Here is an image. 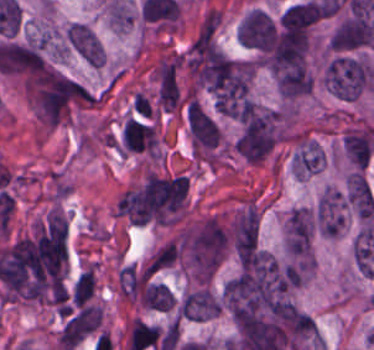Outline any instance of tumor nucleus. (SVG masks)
I'll use <instances>...</instances> for the list:
<instances>
[{
  "mask_svg": "<svg viewBox=\"0 0 374 350\" xmlns=\"http://www.w3.org/2000/svg\"><path fill=\"white\" fill-rule=\"evenodd\" d=\"M231 239L240 265L260 245V215L253 203H246L236 216Z\"/></svg>",
  "mask_w": 374,
  "mask_h": 350,
  "instance_id": "5ab6c2c4",
  "label": "tumor nucleus"
},
{
  "mask_svg": "<svg viewBox=\"0 0 374 350\" xmlns=\"http://www.w3.org/2000/svg\"><path fill=\"white\" fill-rule=\"evenodd\" d=\"M186 122L194 149L211 150L220 143V128L215 118L195 99H188Z\"/></svg>",
  "mask_w": 374,
  "mask_h": 350,
  "instance_id": "2cbd58db",
  "label": "tumor nucleus"
},
{
  "mask_svg": "<svg viewBox=\"0 0 374 350\" xmlns=\"http://www.w3.org/2000/svg\"><path fill=\"white\" fill-rule=\"evenodd\" d=\"M102 320V305L83 304L66 316L58 346L61 350H73L97 329Z\"/></svg>",
  "mask_w": 374,
  "mask_h": 350,
  "instance_id": "8643909e",
  "label": "tumor nucleus"
},
{
  "mask_svg": "<svg viewBox=\"0 0 374 350\" xmlns=\"http://www.w3.org/2000/svg\"><path fill=\"white\" fill-rule=\"evenodd\" d=\"M96 275L94 265L80 273L74 283L71 298L75 306H81L95 293Z\"/></svg>",
  "mask_w": 374,
  "mask_h": 350,
  "instance_id": "8087334f",
  "label": "tumor nucleus"
},
{
  "mask_svg": "<svg viewBox=\"0 0 374 350\" xmlns=\"http://www.w3.org/2000/svg\"><path fill=\"white\" fill-rule=\"evenodd\" d=\"M323 79L330 93L342 99H358L374 89L373 67L350 53L332 56Z\"/></svg>",
  "mask_w": 374,
  "mask_h": 350,
  "instance_id": "2f306a5c",
  "label": "tumor nucleus"
},
{
  "mask_svg": "<svg viewBox=\"0 0 374 350\" xmlns=\"http://www.w3.org/2000/svg\"><path fill=\"white\" fill-rule=\"evenodd\" d=\"M66 40L75 52L82 56L93 66L103 63L102 42L85 22H71L66 31Z\"/></svg>",
  "mask_w": 374,
  "mask_h": 350,
  "instance_id": "2083b535",
  "label": "tumor nucleus"
},
{
  "mask_svg": "<svg viewBox=\"0 0 374 350\" xmlns=\"http://www.w3.org/2000/svg\"><path fill=\"white\" fill-rule=\"evenodd\" d=\"M374 35V25L361 15H348L329 39L334 51L350 52L367 46Z\"/></svg>",
  "mask_w": 374,
  "mask_h": 350,
  "instance_id": "3d1891a8",
  "label": "tumor nucleus"
}]
</instances>
